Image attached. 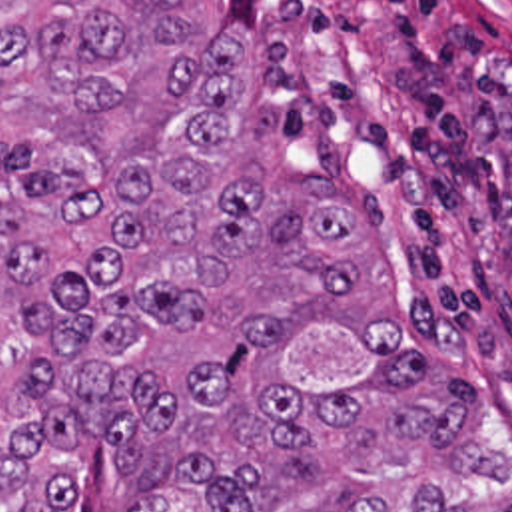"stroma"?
<instances>
[{"mask_svg":"<svg viewBox=\"0 0 512 512\" xmlns=\"http://www.w3.org/2000/svg\"><path fill=\"white\" fill-rule=\"evenodd\" d=\"M189 18L243 48L287 168L333 178L353 210L335 310L397 318L399 347L480 399L508 477L446 499L512 495V0H189Z\"/></svg>","mask_w":512,"mask_h":512,"instance_id":"stroma-1","label":"stroma"}]
</instances>
